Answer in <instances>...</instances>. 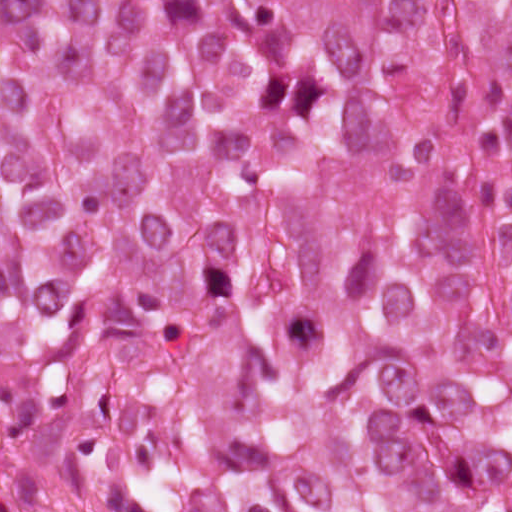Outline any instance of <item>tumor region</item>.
Listing matches in <instances>:
<instances>
[{"mask_svg":"<svg viewBox=\"0 0 512 512\" xmlns=\"http://www.w3.org/2000/svg\"><path fill=\"white\" fill-rule=\"evenodd\" d=\"M0 445L41 512H512V0H0Z\"/></svg>","mask_w":512,"mask_h":512,"instance_id":"obj_1","label":"tumor region"}]
</instances>
